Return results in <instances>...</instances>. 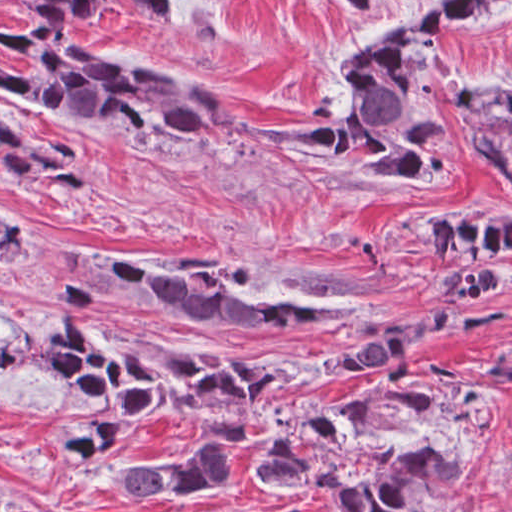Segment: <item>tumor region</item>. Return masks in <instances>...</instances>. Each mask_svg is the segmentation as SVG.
<instances>
[{"mask_svg": "<svg viewBox=\"0 0 512 512\" xmlns=\"http://www.w3.org/2000/svg\"><path fill=\"white\" fill-rule=\"evenodd\" d=\"M22 5L28 26L1 18V42L25 63L1 64V85L22 100L72 121L121 125L189 154L235 138L246 147L286 144L309 153L348 181L438 180L453 152L443 123L471 130L479 159L512 180V86L477 90L434 82L426 54L440 27L487 16L506 0H431L402 27L353 48L314 95L306 128L255 125L232 93L192 71L125 68L95 62L75 28L112 15L109 0H4ZM162 25H174L180 0H130ZM350 14H369L380 0H337ZM1 171L35 190L66 196L89 192L87 153L57 139L28 134L1 115ZM449 295L447 316L425 323L370 322L341 308L282 291L235 287L194 263L154 265L98 256L89 275L55 282L58 296L79 305L196 332L269 327L318 331L342 321L334 335L366 342L357 355L298 367L276 361L175 351L119 339L90 320L66 324L42 349L46 376H61L82 403L80 429L62 452L78 469L118 450L143 418H190L235 442L248 440L255 415L273 398L330 383L356 371L379 373L363 390L285 415L261 476L302 490L329 489L346 512H453L458 480L471 463L438 447L394 450L380 445L407 430L437 396L421 388L409 360L434 334L460 343L489 334L506 307L484 300L512 280V220H444L429 231ZM19 256V223L1 214V269ZM484 366L512 386V341ZM134 457V456H133ZM119 473L118 485L141 505L199 500L230 472V448L153 458ZM1 512H38L20 505Z\"/></svg>", "mask_w": 512, "mask_h": 512, "instance_id": "obj_1", "label": "tumor region"}]
</instances>
